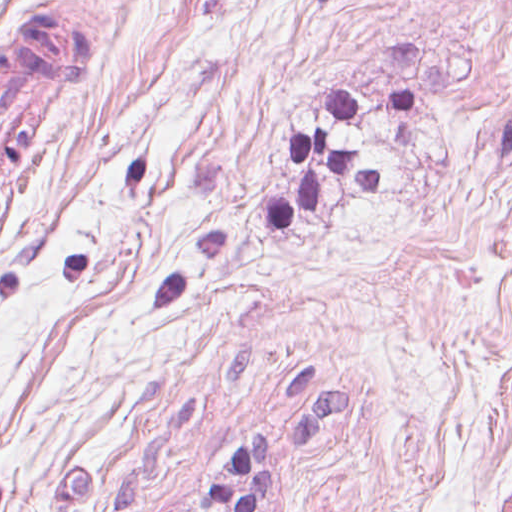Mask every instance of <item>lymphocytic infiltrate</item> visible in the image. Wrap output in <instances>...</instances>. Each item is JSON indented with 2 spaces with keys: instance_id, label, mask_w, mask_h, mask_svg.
I'll return each instance as SVG.
<instances>
[{
  "instance_id": "lymphocytic-infiltrate-1",
  "label": "lymphocytic infiltrate",
  "mask_w": 512,
  "mask_h": 512,
  "mask_svg": "<svg viewBox=\"0 0 512 512\" xmlns=\"http://www.w3.org/2000/svg\"><path fill=\"white\" fill-rule=\"evenodd\" d=\"M288 160L301 167L294 198L273 196L265 209V220L274 230H288L307 210L316 209L324 169L336 167L346 179H355L369 192H381L382 171L364 162L354 149L329 146L327 131L292 134L284 142ZM270 440L251 434L209 477L212 504L220 512H261L272 503V469L268 462Z\"/></svg>"
}]
</instances>
